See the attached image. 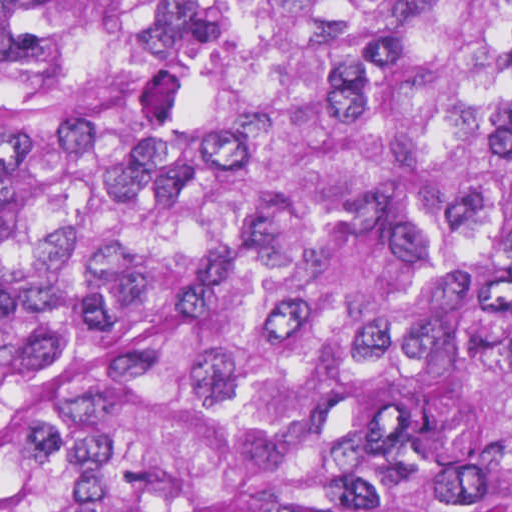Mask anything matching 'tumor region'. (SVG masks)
Wrapping results in <instances>:
<instances>
[{
  "instance_id": "obj_1",
  "label": "tumor region",
  "mask_w": 512,
  "mask_h": 512,
  "mask_svg": "<svg viewBox=\"0 0 512 512\" xmlns=\"http://www.w3.org/2000/svg\"><path fill=\"white\" fill-rule=\"evenodd\" d=\"M0 512H512V0H0Z\"/></svg>"
}]
</instances>
